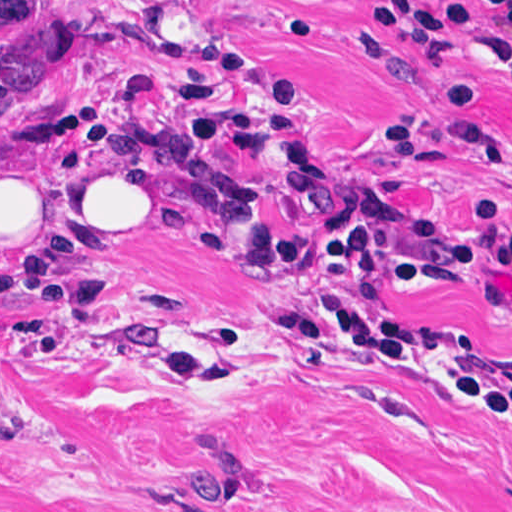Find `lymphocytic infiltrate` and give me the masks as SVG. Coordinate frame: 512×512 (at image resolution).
Wrapping results in <instances>:
<instances>
[{
  "label": "lymphocytic infiltrate",
  "instance_id": "obj_1",
  "mask_svg": "<svg viewBox=\"0 0 512 512\" xmlns=\"http://www.w3.org/2000/svg\"><path fill=\"white\" fill-rule=\"evenodd\" d=\"M489 13L494 31L486 34V52L512 80V0H480L453 11L419 0H381L378 17L406 37L415 54L437 59L453 28L468 34L473 7ZM280 33L307 34V18L292 14ZM164 46L177 59L192 61L208 74V82L176 87V95L196 134L213 144H228L239 158L257 151V118L243 97L225 93L222 78L245 75L223 50L170 10ZM350 54L362 57L387 51L368 27H358ZM273 135L288 167V199L301 223L328 213L341 193V178L308 139L301 117L274 99ZM477 211V210H476ZM487 229L466 235L429 216L410 235L399 238L370 228L333 231L312 255V276L319 300L285 303L282 324L288 339L317 350L337 342L362 348L403 366L413 348L411 331L387 323L336 293L332 283L342 277L383 274L388 282L409 289H430L452 283L465 271L491 266L512 276V226L477 211ZM198 253L210 261L243 267L252 273L272 271L293 257L290 243L263 228L255 190L236 185L225 193L196 236ZM484 301L491 313L512 323V302L488 289ZM449 385L468 395L476 407L512 415V377L501 380L481 372H464Z\"/></svg>",
  "mask_w": 512,
  "mask_h": 512
}]
</instances>
